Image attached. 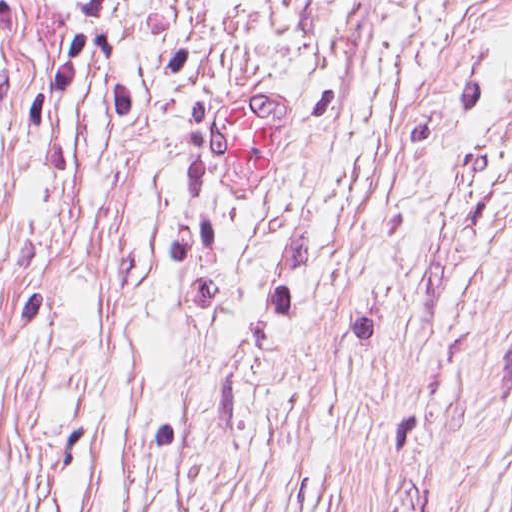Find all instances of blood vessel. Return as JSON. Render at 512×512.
Wrapping results in <instances>:
<instances>
[{
  "label": "blood vessel",
  "instance_id": "1",
  "mask_svg": "<svg viewBox=\"0 0 512 512\" xmlns=\"http://www.w3.org/2000/svg\"><path fill=\"white\" fill-rule=\"evenodd\" d=\"M256 91L230 101L214 127L218 160L243 195H260L291 136V100Z\"/></svg>",
  "mask_w": 512,
  "mask_h": 512
}]
</instances>
